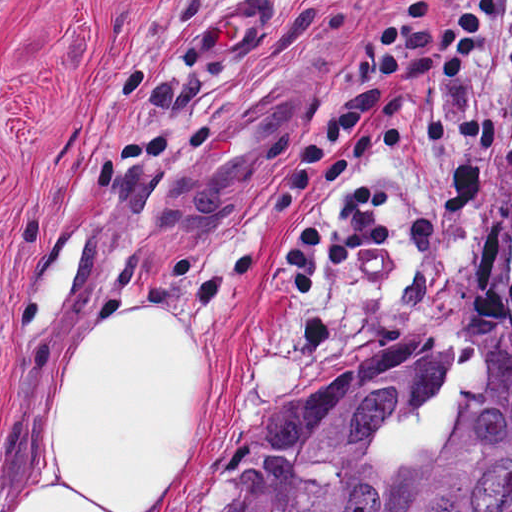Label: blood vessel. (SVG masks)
<instances>
[{"instance_id": "1", "label": "blood vessel", "mask_w": 512, "mask_h": 512, "mask_svg": "<svg viewBox=\"0 0 512 512\" xmlns=\"http://www.w3.org/2000/svg\"><path fill=\"white\" fill-rule=\"evenodd\" d=\"M232 5L188 32L173 54L175 86H198L267 32L264 5ZM266 99L217 129L186 162L171 207L183 229L238 212L282 155L311 105L309 91L264 89Z\"/></svg>"}]
</instances>
